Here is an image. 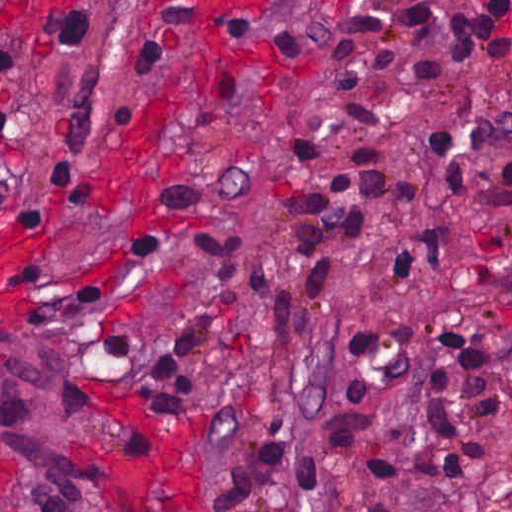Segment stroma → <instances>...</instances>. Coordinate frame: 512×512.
I'll list each match as a JSON object with an SVG mask.
<instances>
[{"instance_id":"1","label":"stroma","mask_w":512,"mask_h":512,"mask_svg":"<svg viewBox=\"0 0 512 512\" xmlns=\"http://www.w3.org/2000/svg\"><path fill=\"white\" fill-rule=\"evenodd\" d=\"M448 1L359 0L347 10L336 0H246L223 28V60L185 77L168 142L126 193L106 185L103 165L200 40L209 25L202 9L193 0L0 5V104L13 112L56 23L79 18L92 39V106L74 140L0 135V323L56 342L58 403L78 411L70 432L78 502L22 477L0 440V512H306L312 433L363 375L512 351V223L433 205L431 141L442 129L459 134L471 183L512 164V141L479 153L470 141L476 122L512 115V36L498 32L510 0H459L493 40L486 62L410 81L405 69L419 59L405 55L327 94L377 113L380 130L315 118L323 158L298 180L302 133L345 32ZM363 150L381 162L382 198L328 290L309 295L294 229L281 219L292 197L333 180ZM428 216L451 240L448 276L441 285L415 267L401 290H389L377 274L403 259ZM200 228L239 236L245 317L206 348L192 374L196 407L176 416L153 403L141 366L194 324L211 279L194 242ZM261 285L316 317L298 330L270 325ZM322 313L333 315L317 321ZM449 320L486 337L436 345ZM355 324L381 331L384 343L364 347ZM397 512H512V429L484 438V473L416 487Z\"/></svg>"}]
</instances>
